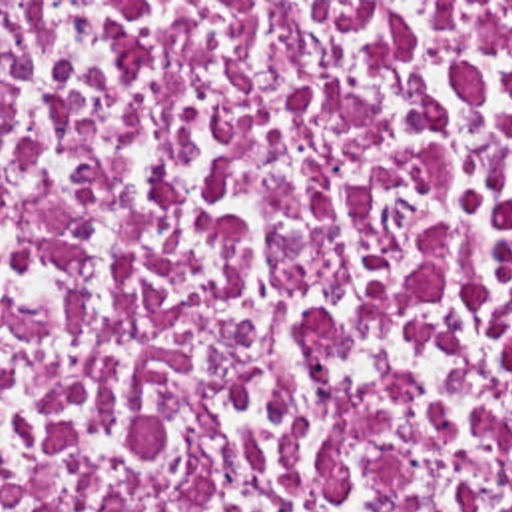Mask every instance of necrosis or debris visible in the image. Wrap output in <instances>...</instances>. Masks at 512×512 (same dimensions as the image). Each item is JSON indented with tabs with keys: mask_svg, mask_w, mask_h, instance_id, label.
Masks as SVG:
<instances>
[{
	"mask_svg": "<svg viewBox=\"0 0 512 512\" xmlns=\"http://www.w3.org/2000/svg\"><path fill=\"white\" fill-rule=\"evenodd\" d=\"M0 512H512V2H0Z\"/></svg>",
	"mask_w": 512,
	"mask_h": 512,
	"instance_id": "1",
	"label": "necrosis or debris"
}]
</instances>
